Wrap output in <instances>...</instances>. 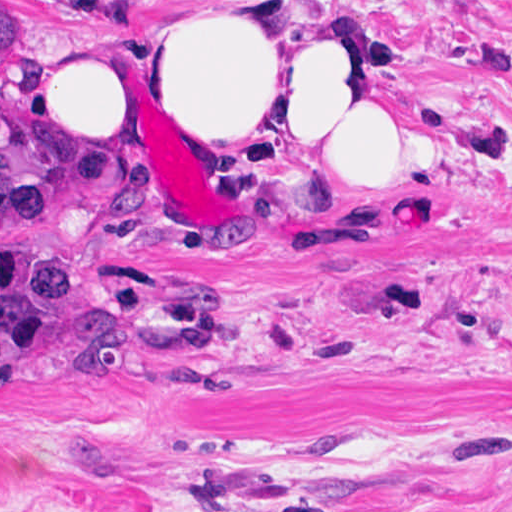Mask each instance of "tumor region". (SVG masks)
<instances>
[{
  "label": "tumor region",
  "mask_w": 512,
  "mask_h": 512,
  "mask_svg": "<svg viewBox=\"0 0 512 512\" xmlns=\"http://www.w3.org/2000/svg\"><path fill=\"white\" fill-rule=\"evenodd\" d=\"M38 46L28 0H0V54ZM40 104L0 89V235L60 226L83 174L50 160L34 129ZM145 324L88 292L74 277L0 249V380L49 387L138 380Z\"/></svg>",
  "instance_id": "obj_1"
}]
</instances>
